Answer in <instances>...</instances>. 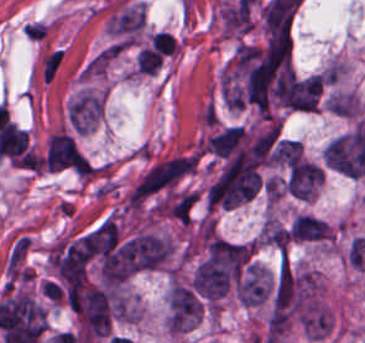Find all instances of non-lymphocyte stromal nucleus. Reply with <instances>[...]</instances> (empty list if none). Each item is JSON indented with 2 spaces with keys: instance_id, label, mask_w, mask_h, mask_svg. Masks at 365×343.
Segmentation results:
<instances>
[{
  "instance_id": "dd21d789",
  "label": "non-lymphocyte stromal nucleus",
  "mask_w": 365,
  "mask_h": 343,
  "mask_svg": "<svg viewBox=\"0 0 365 343\" xmlns=\"http://www.w3.org/2000/svg\"><path fill=\"white\" fill-rule=\"evenodd\" d=\"M62 58V50H55L49 54L42 69V80L49 81Z\"/></svg>"
}]
</instances>
